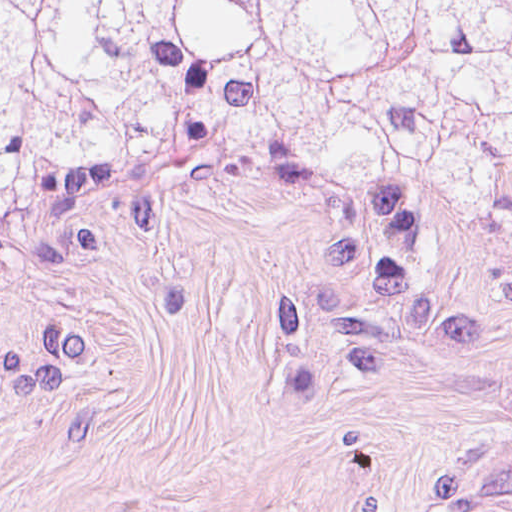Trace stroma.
I'll return each mask as SVG.
<instances>
[{
    "label": "stroma",
    "instance_id": "35a3bbf8",
    "mask_svg": "<svg viewBox=\"0 0 512 512\" xmlns=\"http://www.w3.org/2000/svg\"><path fill=\"white\" fill-rule=\"evenodd\" d=\"M0 512H512V228L193 137L0 209Z\"/></svg>",
    "mask_w": 512,
    "mask_h": 512
}]
</instances>
